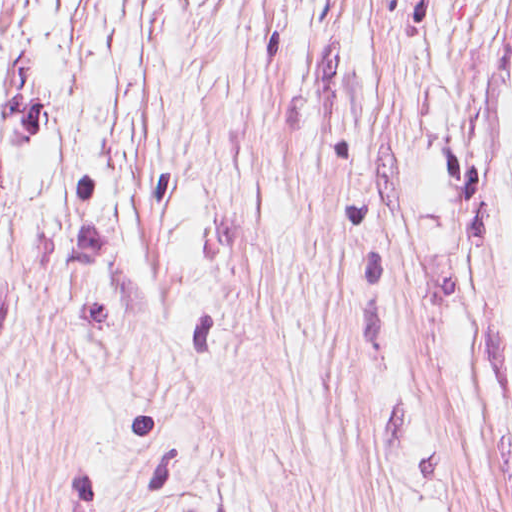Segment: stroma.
<instances>
[{"label":"stroma","mask_w":512,"mask_h":512,"mask_svg":"<svg viewBox=\"0 0 512 512\" xmlns=\"http://www.w3.org/2000/svg\"><path fill=\"white\" fill-rule=\"evenodd\" d=\"M0 512H512V0H0Z\"/></svg>","instance_id":"1"}]
</instances>
